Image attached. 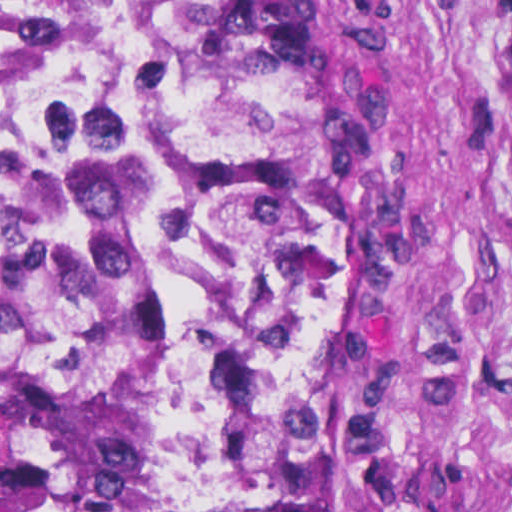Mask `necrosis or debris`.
<instances>
[{"label": "necrosis or debris", "instance_id": "1", "mask_svg": "<svg viewBox=\"0 0 512 512\" xmlns=\"http://www.w3.org/2000/svg\"><path fill=\"white\" fill-rule=\"evenodd\" d=\"M155 66L145 0H0V177L130 101Z\"/></svg>", "mask_w": 512, "mask_h": 512}]
</instances>
